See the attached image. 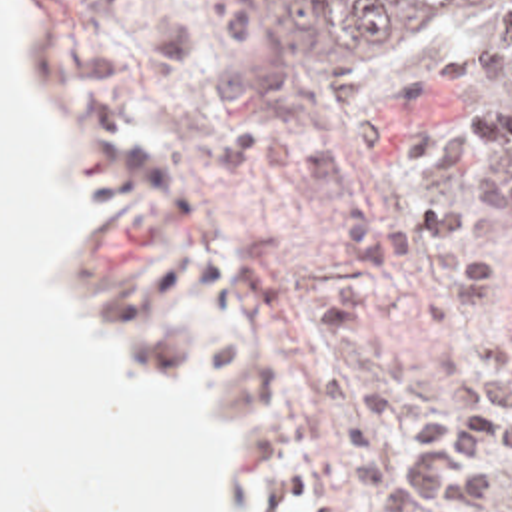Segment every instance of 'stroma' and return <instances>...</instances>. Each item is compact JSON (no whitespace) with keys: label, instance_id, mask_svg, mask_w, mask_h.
<instances>
[{"label":"stroma","instance_id":"stroma-1","mask_svg":"<svg viewBox=\"0 0 512 512\" xmlns=\"http://www.w3.org/2000/svg\"><path fill=\"white\" fill-rule=\"evenodd\" d=\"M55 69V143L97 209L63 263V297L129 367L175 376L190 359L198 440L224 456L236 512H368L350 484L336 418L302 367L342 357L306 313L366 295L350 259L348 205L288 181L226 173L220 139L268 133L300 151L352 145L370 117L466 125L494 109L496 147L448 177H376L472 213L478 251L510 287L438 333L422 277L398 269L370 317L428 406L456 410L442 369H492L512 321V99L496 67L452 27L394 35L334 63L274 41L260 0H25ZM480 512H512V468Z\"/></svg>","mask_w":512,"mask_h":512}]
</instances>
